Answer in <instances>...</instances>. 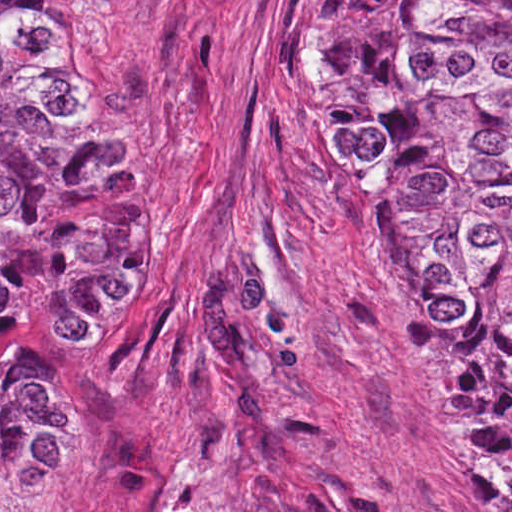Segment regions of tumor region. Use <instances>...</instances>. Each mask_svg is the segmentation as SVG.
I'll use <instances>...</instances> for the list:
<instances>
[{"label":"tumor region","instance_id":"e687c5a6","mask_svg":"<svg viewBox=\"0 0 512 512\" xmlns=\"http://www.w3.org/2000/svg\"><path fill=\"white\" fill-rule=\"evenodd\" d=\"M56 18L0 0V340L25 329L18 303H117L159 240L122 52ZM321 32L330 145L378 175V238L512 512V0H323ZM75 462L64 395L0 362V499L47 507Z\"/></svg>","mask_w":512,"mask_h":512}]
</instances>
